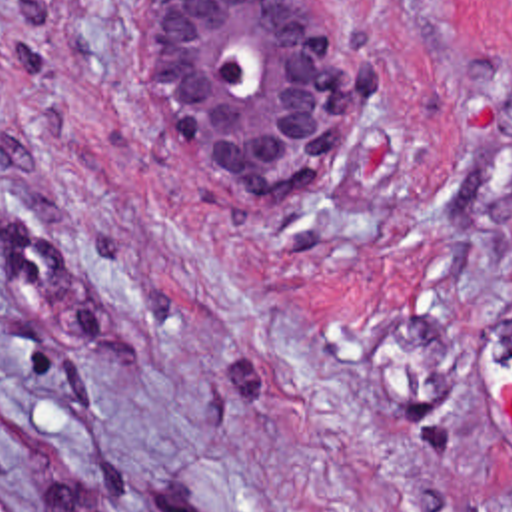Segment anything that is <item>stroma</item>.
<instances>
[{"label":"stroma","mask_w":512,"mask_h":512,"mask_svg":"<svg viewBox=\"0 0 512 512\" xmlns=\"http://www.w3.org/2000/svg\"><path fill=\"white\" fill-rule=\"evenodd\" d=\"M319 1L253 199L143 0H0V512H512V0Z\"/></svg>","instance_id":"stroma-1"}]
</instances>
